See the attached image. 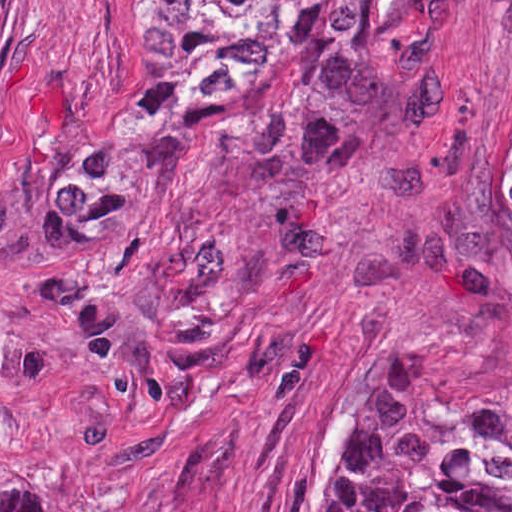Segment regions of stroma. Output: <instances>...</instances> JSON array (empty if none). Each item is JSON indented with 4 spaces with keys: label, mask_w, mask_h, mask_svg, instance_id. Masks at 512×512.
I'll list each match as a JSON object with an SVG mask.
<instances>
[{
    "label": "stroma",
    "mask_w": 512,
    "mask_h": 512,
    "mask_svg": "<svg viewBox=\"0 0 512 512\" xmlns=\"http://www.w3.org/2000/svg\"><path fill=\"white\" fill-rule=\"evenodd\" d=\"M159 0H6L0 15V464L51 512H323L364 430L512 399V0H354L376 65L330 143L167 124L113 199L109 260L201 229L228 342L116 411L93 333L39 267L70 172L148 62Z\"/></svg>",
    "instance_id": "stroma-1"
}]
</instances>
